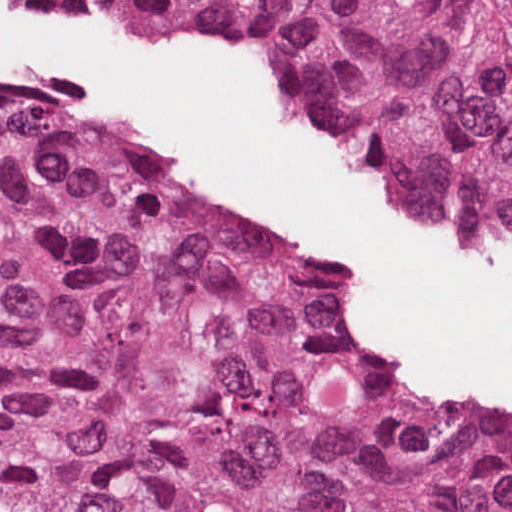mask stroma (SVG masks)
Listing matches in <instances>:
<instances>
[{
  "label": "stroma",
  "mask_w": 512,
  "mask_h": 512,
  "mask_svg": "<svg viewBox=\"0 0 512 512\" xmlns=\"http://www.w3.org/2000/svg\"><path fill=\"white\" fill-rule=\"evenodd\" d=\"M0 1L259 58L305 135L377 178L427 232L512 273V0ZM0 88L76 118L111 174L309 269L306 313L357 374L512 426L511 415L379 351L348 295L358 267L352 253L262 227L180 180L105 105L2 68Z\"/></svg>",
  "instance_id": "35a3bbf8"
}]
</instances>
